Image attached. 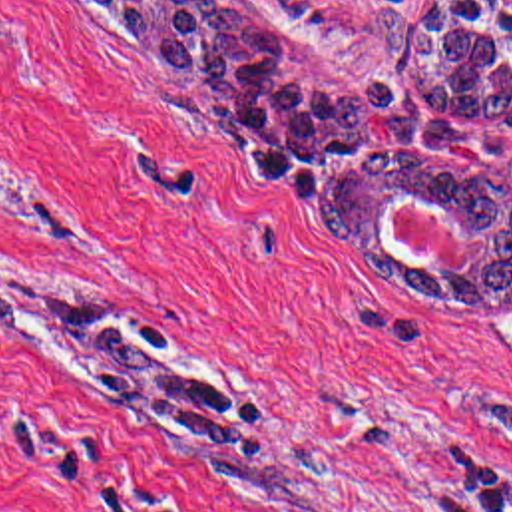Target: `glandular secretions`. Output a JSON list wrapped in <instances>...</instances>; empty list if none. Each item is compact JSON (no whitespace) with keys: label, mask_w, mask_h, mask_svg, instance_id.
I'll return each instance as SVG.
<instances>
[{"label":"glandular secretions","mask_w":512,"mask_h":512,"mask_svg":"<svg viewBox=\"0 0 512 512\" xmlns=\"http://www.w3.org/2000/svg\"><path fill=\"white\" fill-rule=\"evenodd\" d=\"M131 1V3H149V0H127ZM393 206H395V202L389 206V210H387V216H385V224H387V228H389V232L393 234V238L399 242V230H397V222H395V214H393ZM445 216H449L451 220H455L453 218V214L449 212V210H443V208H439ZM469 236V260H471V256L477 252V250H481V240L477 238V236H471V234H467Z\"/></svg>","instance_id":"1"}]
</instances>
